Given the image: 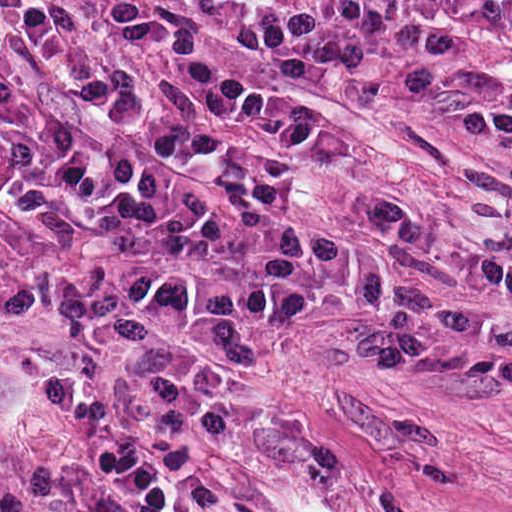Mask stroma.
Listing matches in <instances>:
<instances>
[{"mask_svg":"<svg viewBox=\"0 0 512 512\" xmlns=\"http://www.w3.org/2000/svg\"><path fill=\"white\" fill-rule=\"evenodd\" d=\"M325 102L357 178L350 258L330 218L321 302L238 310L183 361L254 456L185 512H512V66L470 71L441 137Z\"/></svg>","mask_w":512,"mask_h":512,"instance_id":"obj_1","label":"stroma"}]
</instances>
